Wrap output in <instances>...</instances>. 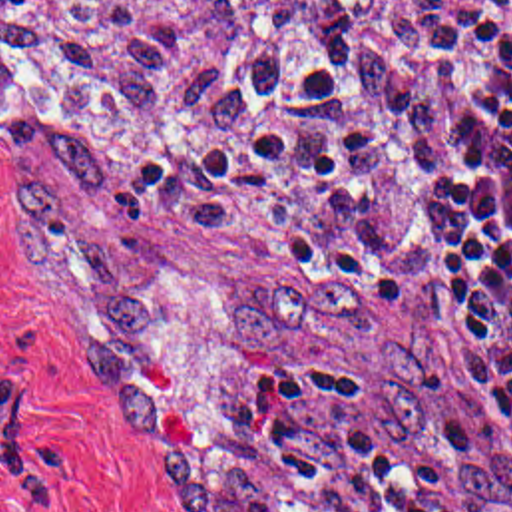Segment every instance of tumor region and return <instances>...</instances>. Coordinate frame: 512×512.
<instances>
[{
	"label": "tumor region",
	"mask_w": 512,
	"mask_h": 512,
	"mask_svg": "<svg viewBox=\"0 0 512 512\" xmlns=\"http://www.w3.org/2000/svg\"><path fill=\"white\" fill-rule=\"evenodd\" d=\"M328 1L394 135L418 133L465 0ZM346 31L314 0H0L5 151L81 191L9 199L71 252L105 336L85 378L135 448L159 444L137 338L165 268L127 195L169 227L278 246L306 288L240 296L226 338L280 354L334 342L388 428L431 444L433 312L376 314L338 264L344 244H392L422 205L356 97Z\"/></svg>",
	"instance_id": "1"
}]
</instances>
